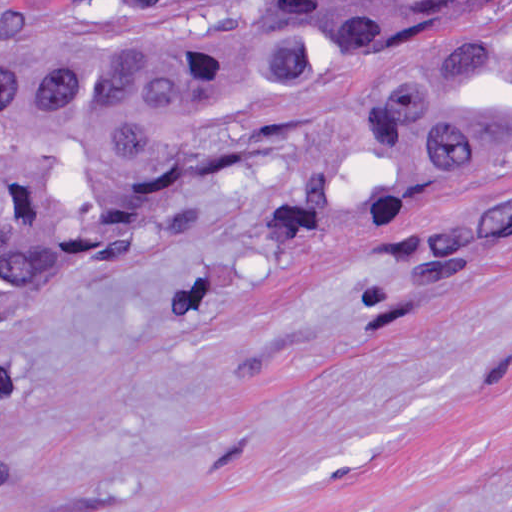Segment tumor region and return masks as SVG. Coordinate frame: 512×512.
<instances>
[{
    "label": "tumor region",
    "mask_w": 512,
    "mask_h": 512,
    "mask_svg": "<svg viewBox=\"0 0 512 512\" xmlns=\"http://www.w3.org/2000/svg\"><path fill=\"white\" fill-rule=\"evenodd\" d=\"M374 213L512 173V1H0V316L203 187ZM512 228V185L422 237Z\"/></svg>",
    "instance_id": "e687c5a6"
}]
</instances>
